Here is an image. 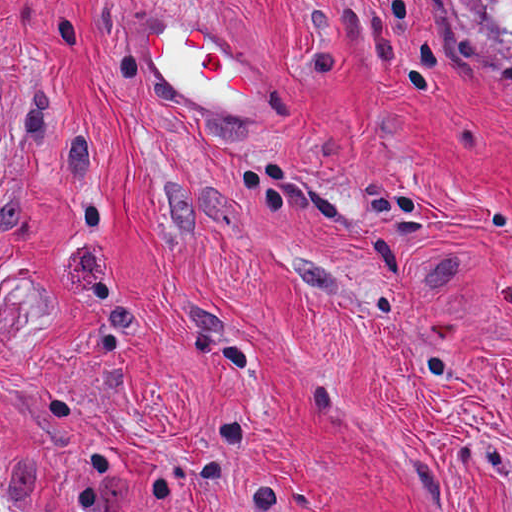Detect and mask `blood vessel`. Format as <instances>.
Here are the masks:
<instances>
[{"mask_svg": "<svg viewBox=\"0 0 512 512\" xmlns=\"http://www.w3.org/2000/svg\"><path fill=\"white\" fill-rule=\"evenodd\" d=\"M146 60L173 97L220 116L260 110V67L230 38L199 19L178 14L149 24ZM4 70L0 67V107Z\"/></svg>", "mask_w": 512, "mask_h": 512, "instance_id": "1", "label": "blood vessel"}]
</instances>
